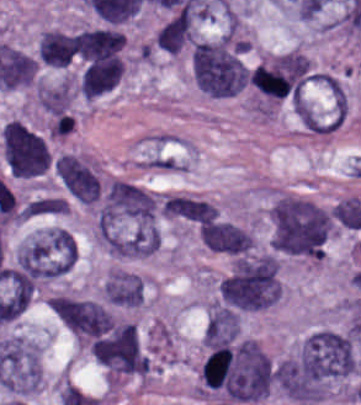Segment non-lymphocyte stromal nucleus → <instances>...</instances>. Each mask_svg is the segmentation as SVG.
<instances>
[{
  "label": "non-lymphocyte stromal nucleus",
  "instance_id": "dd21d789",
  "mask_svg": "<svg viewBox=\"0 0 361 405\" xmlns=\"http://www.w3.org/2000/svg\"><path fill=\"white\" fill-rule=\"evenodd\" d=\"M131 163L140 168L184 171L194 165V146L172 132L145 134Z\"/></svg>",
  "mask_w": 361,
  "mask_h": 405
}]
</instances>
